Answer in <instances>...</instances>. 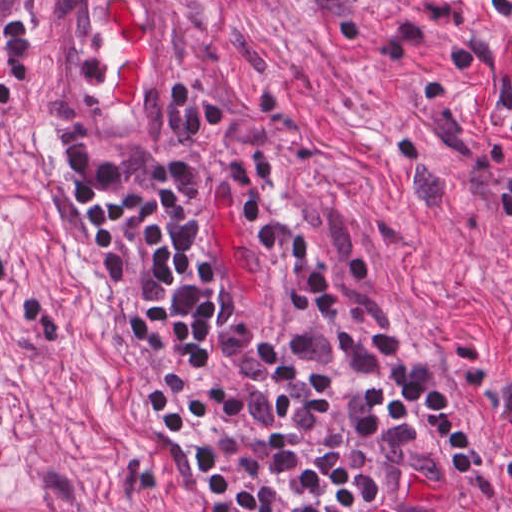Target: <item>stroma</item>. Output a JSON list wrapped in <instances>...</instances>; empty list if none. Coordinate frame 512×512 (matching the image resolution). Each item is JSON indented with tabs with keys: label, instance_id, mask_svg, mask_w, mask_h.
<instances>
[{
	"label": "stroma",
	"instance_id": "35a3bbf8",
	"mask_svg": "<svg viewBox=\"0 0 512 512\" xmlns=\"http://www.w3.org/2000/svg\"><path fill=\"white\" fill-rule=\"evenodd\" d=\"M0 512H65L0 453Z\"/></svg>",
	"mask_w": 512,
	"mask_h": 512
}]
</instances>
